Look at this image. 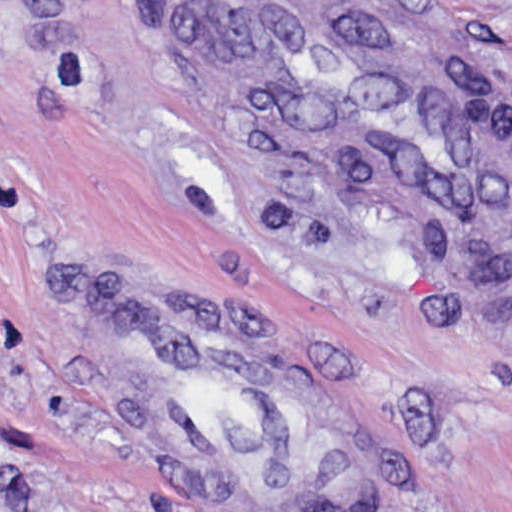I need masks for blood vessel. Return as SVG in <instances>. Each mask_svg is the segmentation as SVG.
<instances>
[{
    "instance_id": "1",
    "label": "blood vessel",
    "mask_w": 512,
    "mask_h": 512,
    "mask_svg": "<svg viewBox=\"0 0 512 512\" xmlns=\"http://www.w3.org/2000/svg\"><path fill=\"white\" fill-rule=\"evenodd\" d=\"M206 88L273 158L437 223H512V91L433 0H155ZM77 356L201 512H347L348 447L314 384L214 296L83 276Z\"/></svg>"
}]
</instances>
